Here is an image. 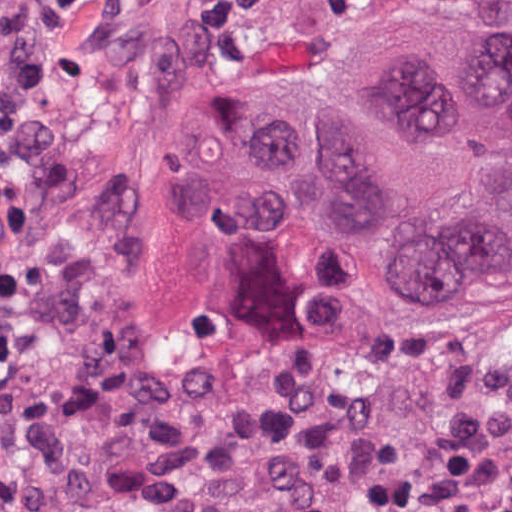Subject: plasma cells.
I'll list each match as a JSON object with an SVG mask.
<instances>
[{"mask_svg":"<svg viewBox=\"0 0 512 512\" xmlns=\"http://www.w3.org/2000/svg\"><path fill=\"white\" fill-rule=\"evenodd\" d=\"M92 1L0 0V235L24 226L13 153L28 136H50L62 41ZM374 426L372 402L359 391L328 373L290 371L207 416L186 469L251 512H349L325 473Z\"/></svg>","mask_w":512,"mask_h":512,"instance_id":"obj_1","label":"plasma cells"}]
</instances>
